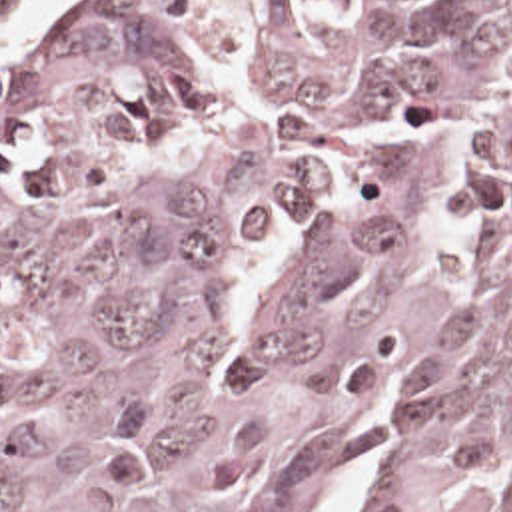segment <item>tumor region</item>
I'll return each mask as SVG.
<instances>
[{
  "label": "tumor region",
  "instance_id": "obj_1",
  "mask_svg": "<svg viewBox=\"0 0 512 512\" xmlns=\"http://www.w3.org/2000/svg\"><path fill=\"white\" fill-rule=\"evenodd\" d=\"M0 512H512V0L0 44Z\"/></svg>",
  "mask_w": 512,
  "mask_h": 512
}]
</instances>
